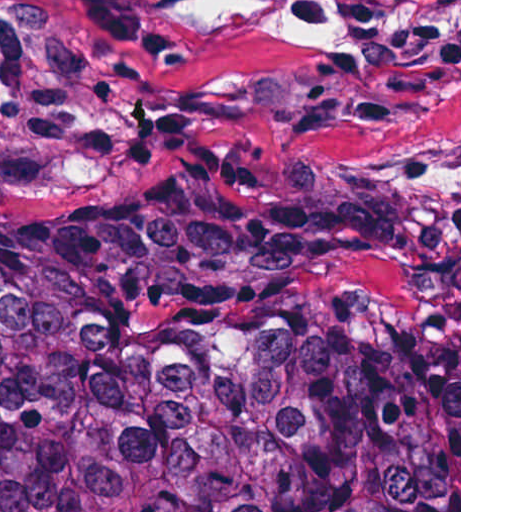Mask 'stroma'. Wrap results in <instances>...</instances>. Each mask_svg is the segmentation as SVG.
I'll list each match as a JSON object with an SVG mask.
<instances>
[{"label": "stroma", "instance_id": "obj_1", "mask_svg": "<svg viewBox=\"0 0 512 512\" xmlns=\"http://www.w3.org/2000/svg\"><path fill=\"white\" fill-rule=\"evenodd\" d=\"M112 2L0 0V249L396 275L459 389L461 512V0H290L344 65L168 21L173 59Z\"/></svg>", "mask_w": 512, "mask_h": 512}]
</instances>
